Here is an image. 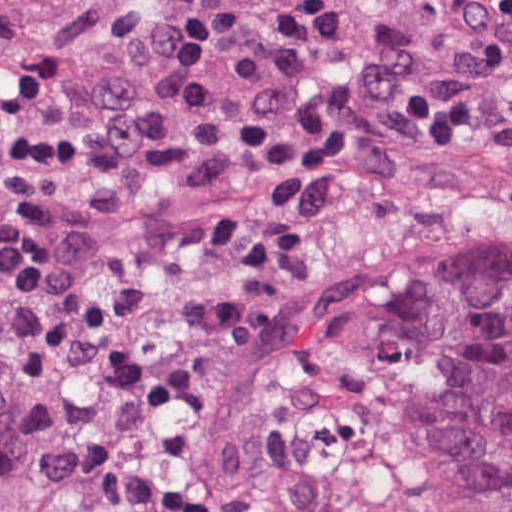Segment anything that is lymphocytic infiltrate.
Returning a JSON list of instances; mask_svg holds the SVG:
<instances>
[{
    "label": "lymphocytic infiltrate",
    "mask_w": 512,
    "mask_h": 512,
    "mask_svg": "<svg viewBox=\"0 0 512 512\" xmlns=\"http://www.w3.org/2000/svg\"><path fill=\"white\" fill-rule=\"evenodd\" d=\"M276 141L291 158L391 141H512V5L365 0L353 61L330 99Z\"/></svg>",
    "instance_id": "lymphocytic-infiltrate-1"
}]
</instances>
